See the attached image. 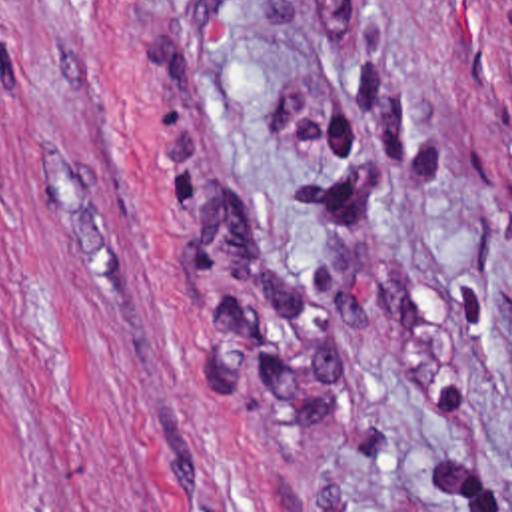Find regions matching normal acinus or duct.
Wrapping results in <instances>:
<instances>
[{
  "label": "normal acinus or duct",
  "mask_w": 512,
  "mask_h": 512,
  "mask_svg": "<svg viewBox=\"0 0 512 512\" xmlns=\"http://www.w3.org/2000/svg\"><path fill=\"white\" fill-rule=\"evenodd\" d=\"M490 17L512 59V0H486Z\"/></svg>",
  "instance_id": "obj_1"
}]
</instances>
